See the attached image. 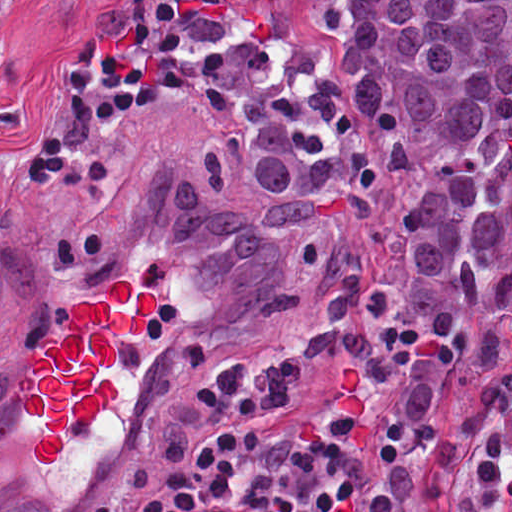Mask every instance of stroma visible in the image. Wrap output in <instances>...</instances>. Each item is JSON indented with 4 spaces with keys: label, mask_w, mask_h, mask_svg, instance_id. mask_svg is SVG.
Here are the masks:
<instances>
[{
    "label": "stroma",
    "mask_w": 512,
    "mask_h": 512,
    "mask_svg": "<svg viewBox=\"0 0 512 512\" xmlns=\"http://www.w3.org/2000/svg\"><path fill=\"white\" fill-rule=\"evenodd\" d=\"M191 25V83L150 117L97 126L91 143L106 174L90 189L43 179L23 167V146L39 112L70 85L74 45L115 41L130 30V0H21L13 38V79L0 86V512H91L111 478L151 446L164 389L218 362H265L284 371L276 404L287 421L323 435L361 462V512L378 499V445L387 430L443 408L473 382L512 368V321L495 335L486 364L443 371L423 415H389L374 370L349 354L317 357L298 345L294 314L245 313L214 327L203 283L183 251L170 245L150 158L186 164L223 201L266 222L253 198L241 138L207 83V33L190 0H172ZM512 29V23H511ZM423 192L422 171L362 195L351 157L325 198L353 239L370 287L403 283V222ZM308 284L297 226H273ZM119 279L156 290L157 309L140 333L115 334L118 396L89 427L66 432L53 464L31 454L41 421L27 414L19 377L47 338H65L78 302H101ZM302 304V305H303ZM433 512H452L451 488Z\"/></svg>",
    "instance_id": "35a3bbf8"
}]
</instances>
